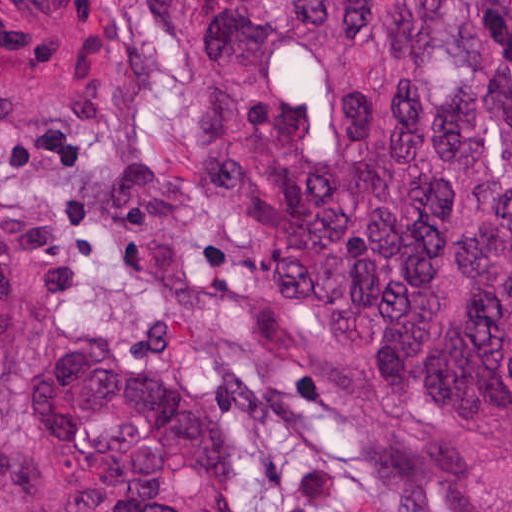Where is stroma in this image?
Instances as JSON below:
<instances>
[{"label": "stroma", "mask_w": 512, "mask_h": 512, "mask_svg": "<svg viewBox=\"0 0 512 512\" xmlns=\"http://www.w3.org/2000/svg\"><path fill=\"white\" fill-rule=\"evenodd\" d=\"M0 99L61 354L156 364L215 405L239 512H467L368 352L274 300L152 0H0Z\"/></svg>", "instance_id": "1"}]
</instances>
